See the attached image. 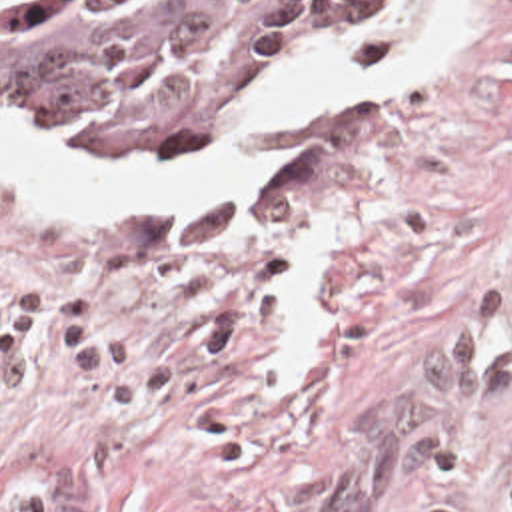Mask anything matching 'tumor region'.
Wrapping results in <instances>:
<instances>
[{
  "mask_svg": "<svg viewBox=\"0 0 512 512\" xmlns=\"http://www.w3.org/2000/svg\"><path fill=\"white\" fill-rule=\"evenodd\" d=\"M382 1L0 0V115L72 149H188Z\"/></svg>",
  "mask_w": 512,
  "mask_h": 512,
  "instance_id": "tumor-region-1",
  "label": "tumor region"
}]
</instances>
